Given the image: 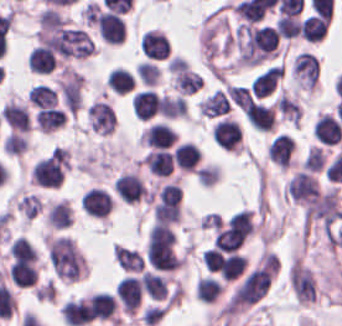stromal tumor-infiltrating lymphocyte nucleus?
<instances>
[{
	"instance_id": "stromal-tumor-infiltrating-lymphocyte-nucleus-6",
	"label": "stromal tumor-infiltrating lymphocyte nucleus",
	"mask_w": 342,
	"mask_h": 326,
	"mask_svg": "<svg viewBox=\"0 0 342 326\" xmlns=\"http://www.w3.org/2000/svg\"><path fill=\"white\" fill-rule=\"evenodd\" d=\"M215 144L226 150H239L241 145L240 124L228 117L217 120L211 130Z\"/></svg>"
},
{
	"instance_id": "stromal-tumor-infiltrating-lymphocyte-nucleus-27",
	"label": "stromal tumor-infiltrating lymphocyte nucleus",
	"mask_w": 342,
	"mask_h": 326,
	"mask_svg": "<svg viewBox=\"0 0 342 326\" xmlns=\"http://www.w3.org/2000/svg\"><path fill=\"white\" fill-rule=\"evenodd\" d=\"M28 96L39 108L50 106L56 102V89L45 82H38L33 84Z\"/></svg>"
},
{
	"instance_id": "stromal-tumor-infiltrating-lymphocyte-nucleus-3",
	"label": "stromal tumor-infiltrating lymphocyte nucleus",
	"mask_w": 342,
	"mask_h": 326,
	"mask_svg": "<svg viewBox=\"0 0 342 326\" xmlns=\"http://www.w3.org/2000/svg\"><path fill=\"white\" fill-rule=\"evenodd\" d=\"M115 293L122 309L127 313H134L143 295L139 275L126 274L117 280Z\"/></svg>"
},
{
	"instance_id": "stromal-tumor-infiltrating-lymphocyte-nucleus-10",
	"label": "stromal tumor-infiltrating lymphocyte nucleus",
	"mask_w": 342,
	"mask_h": 326,
	"mask_svg": "<svg viewBox=\"0 0 342 326\" xmlns=\"http://www.w3.org/2000/svg\"><path fill=\"white\" fill-rule=\"evenodd\" d=\"M1 114L10 129L18 131L30 129V113L26 103L10 99L3 103Z\"/></svg>"
},
{
	"instance_id": "stromal-tumor-infiltrating-lymphocyte-nucleus-26",
	"label": "stromal tumor-infiltrating lymphocyte nucleus",
	"mask_w": 342,
	"mask_h": 326,
	"mask_svg": "<svg viewBox=\"0 0 342 326\" xmlns=\"http://www.w3.org/2000/svg\"><path fill=\"white\" fill-rule=\"evenodd\" d=\"M105 81L107 86L121 94L128 92L134 83L132 72L117 66L111 69Z\"/></svg>"
},
{
	"instance_id": "stromal-tumor-infiltrating-lymphocyte-nucleus-1",
	"label": "stromal tumor-infiltrating lymphocyte nucleus",
	"mask_w": 342,
	"mask_h": 326,
	"mask_svg": "<svg viewBox=\"0 0 342 326\" xmlns=\"http://www.w3.org/2000/svg\"><path fill=\"white\" fill-rule=\"evenodd\" d=\"M291 73L297 87L313 90L318 83L319 63L313 53L301 51L293 57Z\"/></svg>"
},
{
	"instance_id": "stromal-tumor-infiltrating-lymphocyte-nucleus-14",
	"label": "stromal tumor-infiltrating lymphocyte nucleus",
	"mask_w": 342,
	"mask_h": 326,
	"mask_svg": "<svg viewBox=\"0 0 342 326\" xmlns=\"http://www.w3.org/2000/svg\"><path fill=\"white\" fill-rule=\"evenodd\" d=\"M60 312L63 320L71 326H83L92 321L81 296L64 301Z\"/></svg>"
},
{
	"instance_id": "stromal-tumor-infiltrating-lymphocyte-nucleus-22",
	"label": "stromal tumor-infiltrating lymphocyte nucleus",
	"mask_w": 342,
	"mask_h": 326,
	"mask_svg": "<svg viewBox=\"0 0 342 326\" xmlns=\"http://www.w3.org/2000/svg\"><path fill=\"white\" fill-rule=\"evenodd\" d=\"M142 287L147 294L156 299H163L168 292V285L163 274L158 272L143 270L141 277Z\"/></svg>"
},
{
	"instance_id": "stromal-tumor-infiltrating-lymphocyte-nucleus-11",
	"label": "stromal tumor-infiltrating lymphocyte nucleus",
	"mask_w": 342,
	"mask_h": 326,
	"mask_svg": "<svg viewBox=\"0 0 342 326\" xmlns=\"http://www.w3.org/2000/svg\"><path fill=\"white\" fill-rule=\"evenodd\" d=\"M294 138L287 131H280L267 146L268 158L282 166L292 163Z\"/></svg>"
},
{
	"instance_id": "stromal-tumor-infiltrating-lymphocyte-nucleus-2",
	"label": "stromal tumor-infiltrating lymphocyte nucleus",
	"mask_w": 342,
	"mask_h": 326,
	"mask_svg": "<svg viewBox=\"0 0 342 326\" xmlns=\"http://www.w3.org/2000/svg\"><path fill=\"white\" fill-rule=\"evenodd\" d=\"M96 28L100 37L110 43L124 41L126 21L119 12L101 9L95 17Z\"/></svg>"
},
{
	"instance_id": "stromal-tumor-infiltrating-lymphocyte-nucleus-31",
	"label": "stromal tumor-infiltrating lymphocyte nucleus",
	"mask_w": 342,
	"mask_h": 326,
	"mask_svg": "<svg viewBox=\"0 0 342 326\" xmlns=\"http://www.w3.org/2000/svg\"><path fill=\"white\" fill-rule=\"evenodd\" d=\"M324 165V154L318 145H311L305 154L301 167L303 170L317 171Z\"/></svg>"
},
{
	"instance_id": "stromal-tumor-infiltrating-lymphocyte-nucleus-28",
	"label": "stromal tumor-infiltrating lymphocyte nucleus",
	"mask_w": 342,
	"mask_h": 326,
	"mask_svg": "<svg viewBox=\"0 0 342 326\" xmlns=\"http://www.w3.org/2000/svg\"><path fill=\"white\" fill-rule=\"evenodd\" d=\"M40 30H50L64 27L65 16L57 7H44L40 10L38 16Z\"/></svg>"
},
{
	"instance_id": "stromal-tumor-infiltrating-lymphocyte-nucleus-24",
	"label": "stromal tumor-infiltrating lymphocyte nucleus",
	"mask_w": 342,
	"mask_h": 326,
	"mask_svg": "<svg viewBox=\"0 0 342 326\" xmlns=\"http://www.w3.org/2000/svg\"><path fill=\"white\" fill-rule=\"evenodd\" d=\"M221 291L219 280L210 275H203L196 279L194 295L200 300L212 302L218 298Z\"/></svg>"
},
{
	"instance_id": "stromal-tumor-infiltrating-lymphocyte-nucleus-16",
	"label": "stromal tumor-infiltrating lymphocyte nucleus",
	"mask_w": 342,
	"mask_h": 326,
	"mask_svg": "<svg viewBox=\"0 0 342 326\" xmlns=\"http://www.w3.org/2000/svg\"><path fill=\"white\" fill-rule=\"evenodd\" d=\"M71 220L72 211L67 198H60L49 203L45 216L48 227L66 228Z\"/></svg>"
},
{
	"instance_id": "stromal-tumor-infiltrating-lymphocyte-nucleus-17",
	"label": "stromal tumor-infiltrating lymphocyte nucleus",
	"mask_w": 342,
	"mask_h": 326,
	"mask_svg": "<svg viewBox=\"0 0 342 326\" xmlns=\"http://www.w3.org/2000/svg\"><path fill=\"white\" fill-rule=\"evenodd\" d=\"M55 60L54 53L39 43L30 48L27 66L35 73H50L54 69Z\"/></svg>"
},
{
	"instance_id": "stromal-tumor-infiltrating-lymphocyte-nucleus-23",
	"label": "stromal tumor-infiltrating lymphocyte nucleus",
	"mask_w": 342,
	"mask_h": 326,
	"mask_svg": "<svg viewBox=\"0 0 342 326\" xmlns=\"http://www.w3.org/2000/svg\"><path fill=\"white\" fill-rule=\"evenodd\" d=\"M113 258L125 270H140L144 263V259L139 252L133 248L116 243L113 247Z\"/></svg>"
},
{
	"instance_id": "stromal-tumor-infiltrating-lymphocyte-nucleus-13",
	"label": "stromal tumor-infiltrating lymphocyte nucleus",
	"mask_w": 342,
	"mask_h": 326,
	"mask_svg": "<svg viewBox=\"0 0 342 326\" xmlns=\"http://www.w3.org/2000/svg\"><path fill=\"white\" fill-rule=\"evenodd\" d=\"M132 111L139 119L153 116L159 107V97L154 89L143 88L131 96Z\"/></svg>"
},
{
	"instance_id": "stromal-tumor-infiltrating-lymphocyte-nucleus-15",
	"label": "stromal tumor-infiltrating lymphocyte nucleus",
	"mask_w": 342,
	"mask_h": 326,
	"mask_svg": "<svg viewBox=\"0 0 342 326\" xmlns=\"http://www.w3.org/2000/svg\"><path fill=\"white\" fill-rule=\"evenodd\" d=\"M200 148L193 141H186L174 146L173 159L175 166L182 170L194 171L200 161Z\"/></svg>"
},
{
	"instance_id": "stromal-tumor-infiltrating-lymphocyte-nucleus-29",
	"label": "stromal tumor-infiltrating lymphocyte nucleus",
	"mask_w": 342,
	"mask_h": 326,
	"mask_svg": "<svg viewBox=\"0 0 342 326\" xmlns=\"http://www.w3.org/2000/svg\"><path fill=\"white\" fill-rule=\"evenodd\" d=\"M300 20L295 14H280L275 20V28L278 35L283 38L294 37L299 29Z\"/></svg>"
},
{
	"instance_id": "stromal-tumor-infiltrating-lymphocyte-nucleus-18",
	"label": "stromal tumor-infiltrating lymphocyte nucleus",
	"mask_w": 342,
	"mask_h": 326,
	"mask_svg": "<svg viewBox=\"0 0 342 326\" xmlns=\"http://www.w3.org/2000/svg\"><path fill=\"white\" fill-rule=\"evenodd\" d=\"M143 163L157 176H168L173 172V151L152 149L143 159Z\"/></svg>"
},
{
	"instance_id": "stromal-tumor-infiltrating-lymphocyte-nucleus-30",
	"label": "stromal tumor-infiltrating lymphocyte nucleus",
	"mask_w": 342,
	"mask_h": 326,
	"mask_svg": "<svg viewBox=\"0 0 342 326\" xmlns=\"http://www.w3.org/2000/svg\"><path fill=\"white\" fill-rule=\"evenodd\" d=\"M134 70L142 83L152 87L160 74L157 63L149 60L138 62Z\"/></svg>"
},
{
	"instance_id": "stromal-tumor-infiltrating-lymphocyte-nucleus-25",
	"label": "stromal tumor-infiltrating lymphocyte nucleus",
	"mask_w": 342,
	"mask_h": 326,
	"mask_svg": "<svg viewBox=\"0 0 342 326\" xmlns=\"http://www.w3.org/2000/svg\"><path fill=\"white\" fill-rule=\"evenodd\" d=\"M159 110L168 118L185 116V99L180 94L162 93L159 98Z\"/></svg>"
},
{
	"instance_id": "stromal-tumor-infiltrating-lymphocyte-nucleus-7",
	"label": "stromal tumor-infiltrating lymphocyte nucleus",
	"mask_w": 342,
	"mask_h": 326,
	"mask_svg": "<svg viewBox=\"0 0 342 326\" xmlns=\"http://www.w3.org/2000/svg\"><path fill=\"white\" fill-rule=\"evenodd\" d=\"M319 187L317 176L297 170L290 178L285 192L293 202L304 203Z\"/></svg>"
},
{
	"instance_id": "stromal-tumor-infiltrating-lymphocyte-nucleus-19",
	"label": "stromal tumor-infiltrating lymphocyte nucleus",
	"mask_w": 342,
	"mask_h": 326,
	"mask_svg": "<svg viewBox=\"0 0 342 326\" xmlns=\"http://www.w3.org/2000/svg\"><path fill=\"white\" fill-rule=\"evenodd\" d=\"M34 121L40 131L50 132L61 126L66 116L61 108L51 105L37 110Z\"/></svg>"
},
{
	"instance_id": "stromal-tumor-infiltrating-lymphocyte-nucleus-21",
	"label": "stromal tumor-infiltrating lymphocyte nucleus",
	"mask_w": 342,
	"mask_h": 326,
	"mask_svg": "<svg viewBox=\"0 0 342 326\" xmlns=\"http://www.w3.org/2000/svg\"><path fill=\"white\" fill-rule=\"evenodd\" d=\"M328 24L317 15H309L299 22L298 31L307 42H317L325 33Z\"/></svg>"
},
{
	"instance_id": "stromal-tumor-infiltrating-lymphocyte-nucleus-20",
	"label": "stromal tumor-infiltrating lymphocyte nucleus",
	"mask_w": 342,
	"mask_h": 326,
	"mask_svg": "<svg viewBox=\"0 0 342 326\" xmlns=\"http://www.w3.org/2000/svg\"><path fill=\"white\" fill-rule=\"evenodd\" d=\"M231 108V99L225 89H217L203 98L199 109L201 114L216 116Z\"/></svg>"
},
{
	"instance_id": "stromal-tumor-infiltrating-lymphocyte-nucleus-9",
	"label": "stromal tumor-infiltrating lymphocyte nucleus",
	"mask_w": 342,
	"mask_h": 326,
	"mask_svg": "<svg viewBox=\"0 0 342 326\" xmlns=\"http://www.w3.org/2000/svg\"><path fill=\"white\" fill-rule=\"evenodd\" d=\"M82 208L91 216L103 217L110 209V197L106 188L91 186L81 196Z\"/></svg>"
},
{
	"instance_id": "stromal-tumor-infiltrating-lymphocyte-nucleus-12",
	"label": "stromal tumor-infiltrating lymphocyte nucleus",
	"mask_w": 342,
	"mask_h": 326,
	"mask_svg": "<svg viewBox=\"0 0 342 326\" xmlns=\"http://www.w3.org/2000/svg\"><path fill=\"white\" fill-rule=\"evenodd\" d=\"M342 126L333 114L319 113L314 120L313 135L324 144H336Z\"/></svg>"
},
{
	"instance_id": "stromal-tumor-infiltrating-lymphocyte-nucleus-5",
	"label": "stromal tumor-infiltrating lymphocyte nucleus",
	"mask_w": 342,
	"mask_h": 326,
	"mask_svg": "<svg viewBox=\"0 0 342 326\" xmlns=\"http://www.w3.org/2000/svg\"><path fill=\"white\" fill-rule=\"evenodd\" d=\"M113 191L123 202H136L148 197V192L135 171H122L113 180Z\"/></svg>"
},
{
	"instance_id": "stromal-tumor-infiltrating-lymphocyte-nucleus-8",
	"label": "stromal tumor-infiltrating lymphocyte nucleus",
	"mask_w": 342,
	"mask_h": 326,
	"mask_svg": "<svg viewBox=\"0 0 342 326\" xmlns=\"http://www.w3.org/2000/svg\"><path fill=\"white\" fill-rule=\"evenodd\" d=\"M141 144L157 149H165L178 140L176 134L162 121L148 125L139 138Z\"/></svg>"
},
{
	"instance_id": "stromal-tumor-infiltrating-lymphocyte-nucleus-4",
	"label": "stromal tumor-infiltrating lymphocyte nucleus",
	"mask_w": 342,
	"mask_h": 326,
	"mask_svg": "<svg viewBox=\"0 0 342 326\" xmlns=\"http://www.w3.org/2000/svg\"><path fill=\"white\" fill-rule=\"evenodd\" d=\"M89 320H117L116 298L106 290L84 298Z\"/></svg>"
}]
</instances>
